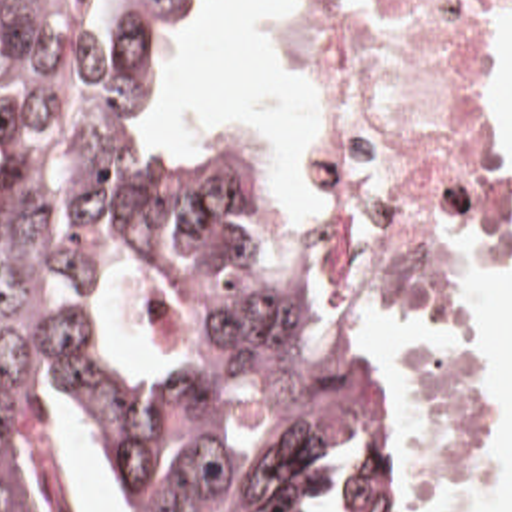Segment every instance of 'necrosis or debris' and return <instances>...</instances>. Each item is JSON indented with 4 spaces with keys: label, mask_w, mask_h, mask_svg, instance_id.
<instances>
[{
    "label": "necrosis or debris",
    "mask_w": 512,
    "mask_h": 512,
    "mask_svg": "<svg viewBox=\"0 0 512 512\" xmlns=\"http://www.w3.org/2000/svg\"><path fill=\"white\" fill-rule=\"evenodd\" d=\"M305 193L323 289L395 369L413 478L478 460L458 317L510 239L490 87L512 0H297Z\"/></svg>",
    "instance_id": "necrosis-or-debris-1"
}]
</instances>
